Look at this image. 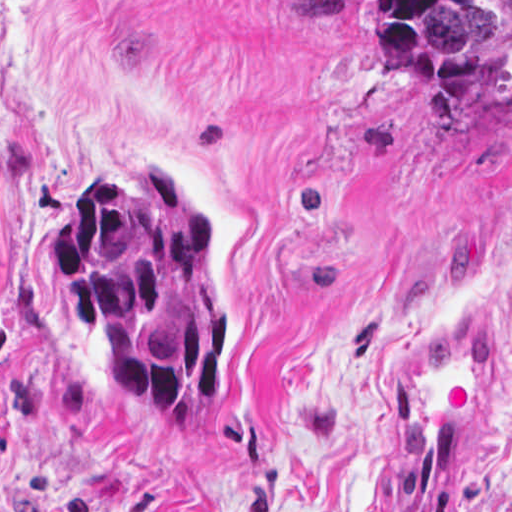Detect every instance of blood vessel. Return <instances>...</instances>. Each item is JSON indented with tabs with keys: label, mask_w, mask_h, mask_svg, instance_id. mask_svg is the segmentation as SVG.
<instances>
[{
	"label": "blood vessel",
	"mask_w": 512,
	"mask_h": 512,
	"mask_svg": "<svg viewBox=\"0 0 512 512\" xmlns=\"http://www.w3.org/2000/svg\"><path fill=\"white\" fill-rule=\"evenodd\" d=\"M499 376L498 339L475 318L424 344L378 446L374 512L459 511Z\"/></svg>",
	"instance_id": "8fb6f2fc"
}]
</instances>
